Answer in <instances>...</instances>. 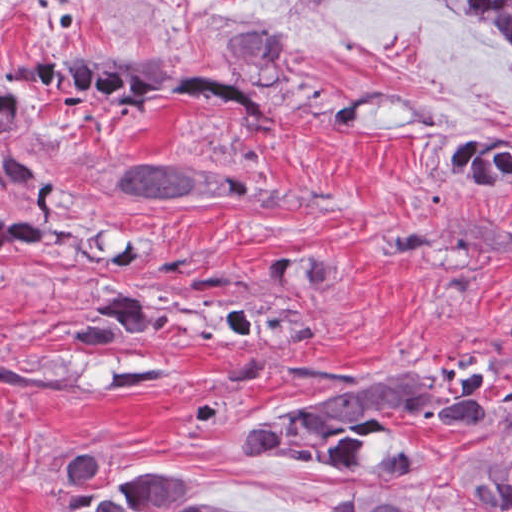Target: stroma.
<instances>
[{
  "instance_id": "stroma-1",
  "label": "stroma",
  "mask_w": 512,
  "mask_h": 512,
  "mask_svg": "<svg viewBox=\"0 0 512 512\" xmlns=\"http://www.w3.org/2000/svg\"><path fill=\"white\" fill-rule=\"evenodd\" d=\"M258 26L297 41L295 79L371 100L335 127L273 95L283 122L255 137L197 106L159 125L64 103L28 149L89 200L145 230L104 266L10 270L0 279V340L20 367L78 374L90 393L0 386V512H48L55 478L104 460L96 486L131 473L195 476L197 497L255 512H339L347 494L414 498L421 512H491L461 476L512 449V406L467 430L392 415L417 452L385 476L326 471L255 454L247 430L271 414L384 377L462 366L486 389H512V264L440 255L380 261L370 244L405 225L452 217L512 226V197L482 201L453 187L434 159L438 138L474 120L512 118V59L474 21L420 0H0V86L22 55L36 61L122 53L130 70L225 76L228 38ZM141 150L234 174L332 205L291 211L246 197L167 211L108 181ZM39 200L0 181V220H25ZM332 248L343 272L325 296V331L290 359L233 345L230 335H148L123 344L69 339L99 285L162 282L199 296L260 284L291 248ZM120 355L166 362L173 383L103 393Z\"/></svg>"
}]
</instances>
